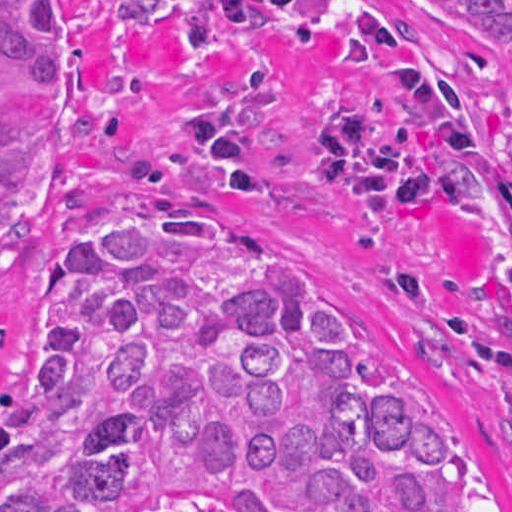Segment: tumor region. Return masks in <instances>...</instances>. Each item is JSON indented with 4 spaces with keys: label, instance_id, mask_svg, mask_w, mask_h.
I'll return each instance as SVG.
<instances>
[{
    "label": "tumor region",
    "instance_id": "obj_1",
    "mask_svg": "<svg viewBox=\"0 0 512 512\" xmlns=\"http://www.w3.org/2000/svg\"><path fill=\"white\" fill-rule=\"evenodd\" d=\"M207 169L374 233L410 317L490 368L512 418V0H162ZM60 131L56 0H0V236ZM59 358L0 391V512H512L426 364L176 200L51 256Z\"/></svg>",
    "mask_w": 512,
    "mask_h": 512
}]
</instances>
